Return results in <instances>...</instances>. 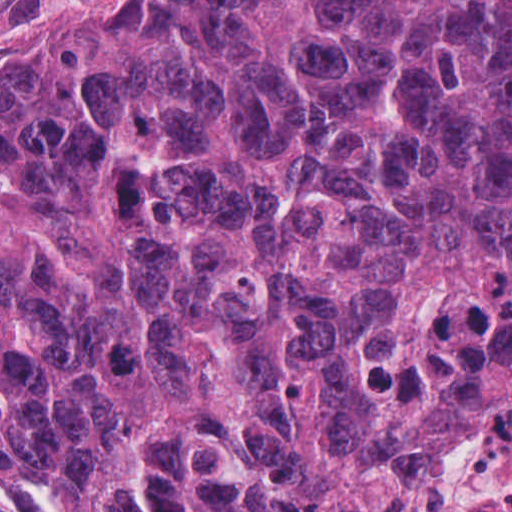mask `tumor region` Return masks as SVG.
Masks as SVG:
<instances>
[{"instance_id":"tumor-region-1","label":"tumor region","mask_w":512,"mask_h":512,"mask_svg":"<svg viewBox=\"0 0 512 512\" xmlns=\"http://www.w3.org/2000/svg\"><path fill=\"white\" fill-rule=\"evenodd\" d=\"M455 319L512 374V0H111L0 56V512H396Z\"/></svg>"}]
</instances>
